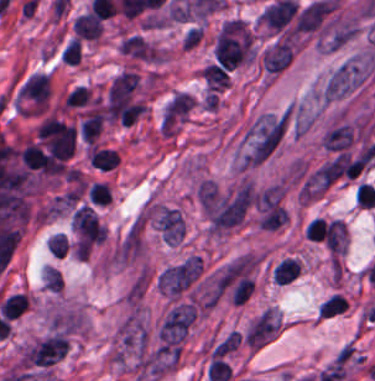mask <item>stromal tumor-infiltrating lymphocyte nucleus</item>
<instances>
[{
  "label": "stromal tumor-infiltrating lymphocyte nucleus",
  "mask_w": 375,
  "mask_h": 381,
  "mask_svg": "<svg viewBox=\"0 0 375 381\" xmlns=\"http://www.w3.org/2000/svg\"><path fill=\"white\" fill-rule=\"evenodd\" d=\"M215 57L224 68H234L249 58V34L243 26H224L215 41Z\"/></svg>",
  "instance_id": "obj_1"
},
{
  "label": "stromal tumor-infiltrating lymphocyte nucleus",
  "mask_w": 375,
  "mask_h": 381,
  "mask_svg": "<svg viewBox=\"0 0 375 381\" xmlns=\"http://www.w3.org/2000/svg\"><path fill=\"white\" fill-rule=\"evenodd\" d=\"M50 93L46 73H33L18 91L22 113H42Z\"/></svg>",
  "instance_id": "obj_2"
},
{
  "label": "stromal tumor-infiltrating lymphocyte nucleus",
  "mask_w": 375,
  "mask_h": 381,
  "mask_svg": "<svg viewBox=\"0 0 375 381\" xmlns=\"http://www.w3.org/2000/svg\"><path fill=\"white\" fill-rule=\"evenodd\" d=\"M300 272V264L292 258H284L274 267L273 276L277 285H284L295 279Z\"/></svg>",
  "instance_id": "obj_3"
},
{
  "label": "stromal tumor-infiltrating lymphocyte nucleus",
  "mask_w": 375,
  "mask_h": 381,
  "mask_svg": "<svg viewBox=\"0 0 375 381\" xmlns=\"http://www.w3.org/2000/svg\"><path fill=\"white\" fill-rule=\"evenodd\" d=\"M26 309V300L21 294L9 295L0 305L2 315L15 319Z\"/></svg>",
  "instance_id": "obj_4"
},
{
  "label": "stromal tumor-infiltrating lymphocyte nucleus",
  "mask_w": 375,
  "mask_h": 381,
  "mask_svg": "<svg viewBox=\"0 0 375 381\" xmlns=\"http://www.w3.org/2000/svg\"><path fill=\"white\" fill-rule=\"evenodd\" d=\"M347 307L346 301L340 294H333L322 304L319 305V316H333L345 311Z\"/></svg>",
  "instance_id": "obj_5"
},
{
  "label": "stromal tumor-infiltrating lymphocyte nucleus",
  "mask_w": 375,
  "mask_h": 381,
  "mask_svg": "<svg viewBox=\"0 0 375 381\" xmlns=\"http://www.w3.org/2000/svg\"><path fill=\"white\" fill-rule=\"evenodd\" d=\"M61 61L76 64L81 61V38L75 36L66 43L61 53Z\"/></svg>",
  "instance_id": "obj_6"
}]
</instances>
